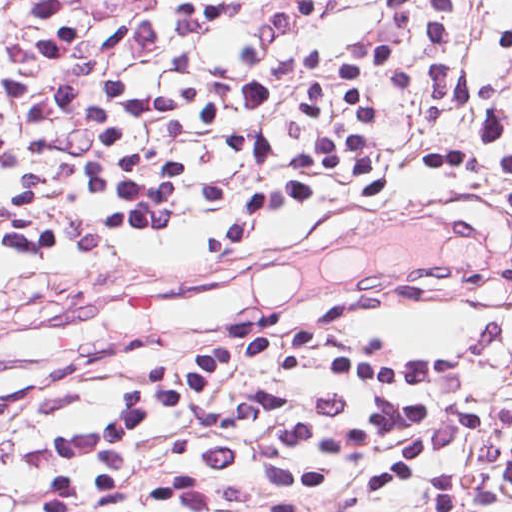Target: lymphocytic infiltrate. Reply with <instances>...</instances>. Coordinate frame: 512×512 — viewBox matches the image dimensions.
<instances>
[{
	"label": "lymphocytic infiltrate",
	"instance_id": "1",
	"mask_svg": "<svg viewBox=\"0 0 512 512\" xmlns=\"http://www.w3.org/2000/svg\"><path fill=\"white\" fill-rule=\"evenodd\" d=\"M0 0V436L63 390L26 512L512 500V370L374 347L512 276V0Z\"/></svg>",
	"mask_w": 512,
	"mask_h": 512
}]
</instances>
